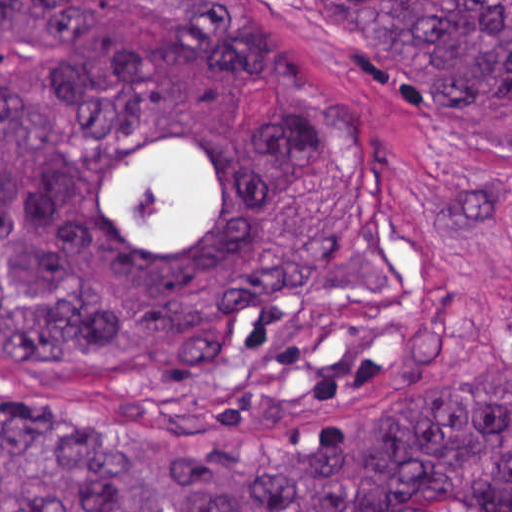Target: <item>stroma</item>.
Instances as JSON below:
<instances>
[{"instance_id": "1", "label": "stroma", "mask_w": 512, "mask_h": 512, "mask_svg": "<svg viewBox=\"0 0 512 512\" xmlns=\"http://www.w3.org/2000/svg\"><path fill=\"white\" fill-rule=\"evenodd\" d=\"M315 78L363 103L394 147V178L438 239L456 298L452 347L399 375L339 430L432 404L512 372V89L487 94L419 90L327 37L304 0H256ZM277 84L245 82L239 119L265 132L279 115ZM0 369L114 430L168 432L122 417L106 375H75L0 355Z\"/></svg>"}]
</instances>
